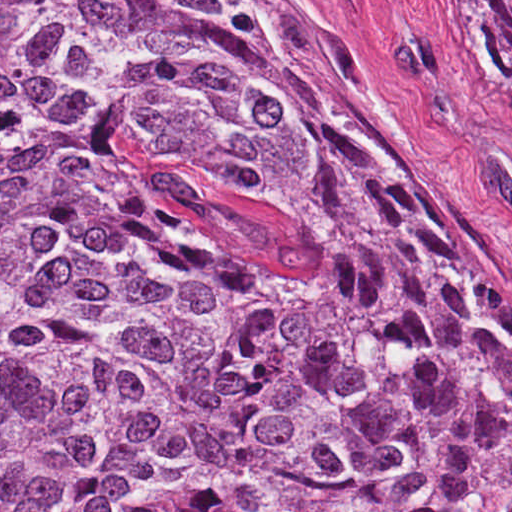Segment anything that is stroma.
Listing matches in <instances>:
<instances>
[{
    "mask_svg": "<svg viewBox=\"0 0 512 512\" xmlns=\"http://www.w3.org/2000/svg\"><path fill=\"white\" fill-rule=\"evenodd\" d=\"M0 1H295L512 312V70L475 5L512 0Z\"/></svg>",
    "mask_w": 512,
    "mask_h": 512,
    "instance_id": "1",
    "label": "stroma"
}]
</instances>
